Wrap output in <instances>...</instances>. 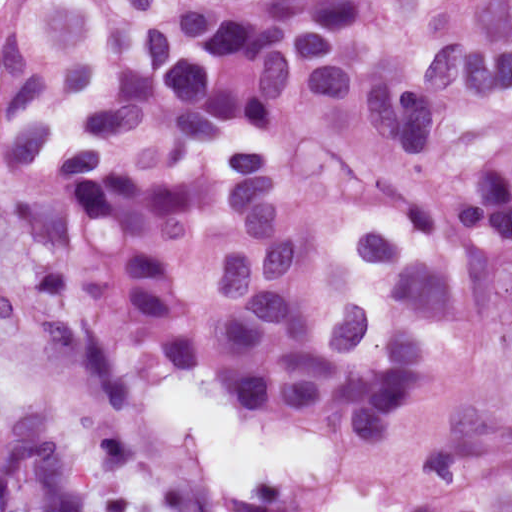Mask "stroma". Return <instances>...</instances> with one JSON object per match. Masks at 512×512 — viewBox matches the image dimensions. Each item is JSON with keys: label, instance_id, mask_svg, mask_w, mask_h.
<instances>
[{"label": "stroma", "instance_id": "1", "mask_svg": "<svg viewBox=\"0 0 512 512\" xmlns=\"http://www.w3.org/2000/svg\"><path fill=\"white\" fill-rule=\"evenodd\" d=\"M235 5L257 0H229ZM29 225L0 202V419L46 398L63 408L101 512H220L194 445L158 437L146 422L160 367L115 395L99 396L70 372L47 325L33 276ZM512 430V354L472 348L459 361L441 434L383 451L369 434L331 436L336 463L315 489L313 512L331 492L358 484L391 492L397 512L420 501L435 453L476 432Z\"/></svg>", "mask_w": 512, "mask_h": 512}]
</instances>
